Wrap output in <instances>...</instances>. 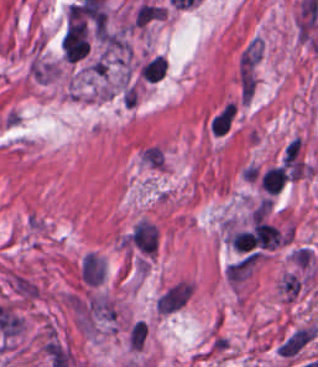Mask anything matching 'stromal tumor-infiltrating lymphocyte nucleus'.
Listing matches in <instances>:
<instances>
[{
  "instance_id": "1",
  "label": "stromal tumor-infiltrating lymphocyte nucleus",
  "mask_w": 318,
  "mask_h": 367,
  "mask_svg": "<svg viewBox=\"0 0 318 367\" xmlns=\"http://www.w3.org/2000/svg\"><path fill=\"white\" fill-rule=\"evenodd\" d=\"M287 179L284 166H271L261 177L262 187L274 195L281 191Z\"/></svg>"
},
{
  "instance_id": "2",
  "label": "stromal tumor-infiltrating lymphocyte nucleus",
  "mask_w": 318,
  "mask_h": 367,
  "mask_svg": "<svg viewBox=\"0 0 318 367\" xmlns=\"http://www.w3.org/2000/svg\"><path fill=\"white\" fill-rule=\"evenodd\" d=\"M167 71V62L161 56L153 57L141 70L142 77L150 82H157Z\"/></svg>"
},
{
  "instance_id": "3",
  "label": "stromal tumor-infiltrating lymphocyte nucleus",
  "mask_w": 318,
  "mask_h": 367,
  "mask_svg": "<svg viewBox=\"0 0 318 367\" xmlns=\"http://www.w3.org/2000/svg\"><path fill=\"white\" fill-rule=\"evenodd\" d=\"M235 112V103H228L212 120L214 134H224L229 130Z\"/></svg>"
},
{
  "instance_id": "4",
  "label": "stromal tumor-infiltrating lymphocyte nucleus",
  "mask_w": 318,
  "mask_h": 367,
  "mask_svg": "<svg viewBox=\"0 0 318 367\" xmlns=\"http://www.w3.org/2000/svg\"><path fill=\"white\" fill-rule=\"evenodd\" d=\"M231 239L236 249L246 252L255 247L252 232L247 230L236 231Z\"/></svg>"
}]
</instances>
